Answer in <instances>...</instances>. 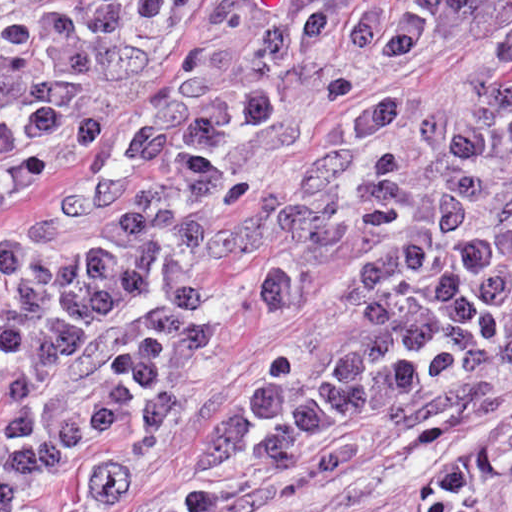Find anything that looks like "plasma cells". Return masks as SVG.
<instances>
[{
	"label": "plasma cells",
	"mask_w": 512,
	"mask_h": 512,
	"mask_svg": "<svg viewBox=\"0 0 512 512\" xmlns=\"http://www.w3.org/2000/svg\"><path fill=\"white\" fill-rule=\"evenodd\" d=\"M183 0H50L0 36V198L83 155L160 63ZM511 0H219L128 137L0 242V512L52 478L124 491L204 392L231 262L319 308L253 355L198 442L229 479L359 459L368 425L428 446L497 415L512 369V41L451 82L354 110L281 197L217 226L248 183L379 73L486 31ZM415 512H512V422L430 467Z\"/></svg>",
	"instance_id": "obj_1"
}]
</instances>
